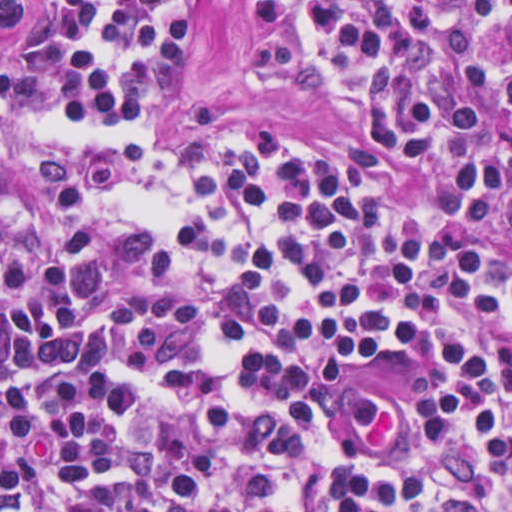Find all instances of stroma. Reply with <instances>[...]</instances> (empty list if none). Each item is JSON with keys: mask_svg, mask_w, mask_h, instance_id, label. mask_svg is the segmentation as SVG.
<instances>
[{"mask_svg": "<svg viewBox=\"0 0 512 512\" xmlns=\"http://www.w3.org/2000/svg\"><path fill=\"white\" fill-rule=\"evenodd\" d=\"M40 0L0 18V51L38 34ZM250 18L240 0H186L183 73L163 98L154 144L176 155L227 139H261L343 157L355 145L349 120L309 90L278 81L253 60ZM27 474V473H26ZM49 494L53 512H66Z\"/></svg>", "mask_w": 512, "mask_h": 512, "instance_id": "1", "label": "stroma"}]
</instances>
